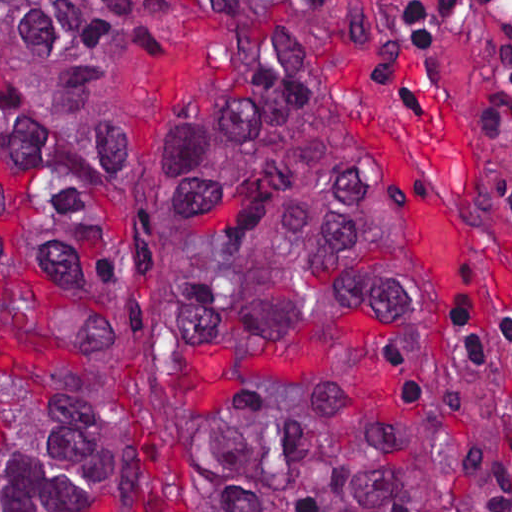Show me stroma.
Segmentation results:
<instances>
[{"label":"stroma","instance_id":"obj_1","mask_svg":"<svg viewBox=\"0 0 512 512\" xmlns=\"http://www.w3.org/2000/svg\"><path fill=\"white\" fill-rule=\"evenodd\" d=\"M0 1H298L356 123L413 178L434 259L460 288L490 512H512L495 329V317L512 311V161L488 105L414 15V1L512 0ZM229 68L215 15L146 50L130 76L128 134L155 165L174 174L188 105Z\"/></svg>","mask_w":512,"mask_h":512}]
</instances>
